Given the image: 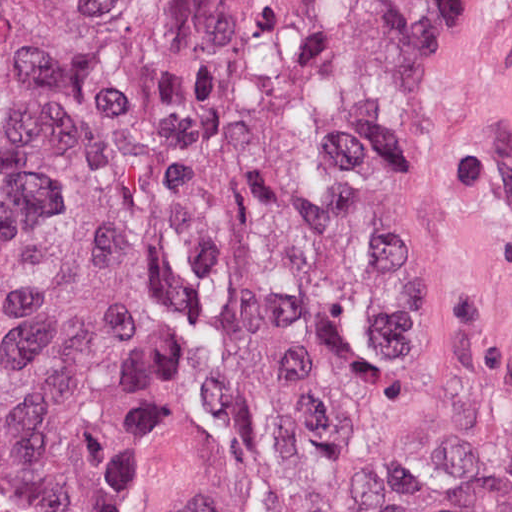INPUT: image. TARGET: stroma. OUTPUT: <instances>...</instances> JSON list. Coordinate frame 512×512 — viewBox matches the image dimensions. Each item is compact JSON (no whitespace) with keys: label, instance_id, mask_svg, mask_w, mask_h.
I'll list each match as a JSON object with an SVG mask.
<instances>
[{"label":"stroma","instance_id":"obj_1","mask_svg":"<svg viewBox=\"0 0 512 512\" xmlns=\"http://www.w3.org/2000/svg\"><path fill=\"white\" fill-rule=\"evenodd\" d=\"M416 259L467 372L512 402V0H460L440 46L423 120ZM151 269L154 364L117 512H152L149 471L173 375L171 312Z\"/></svg>","mask_w":512,"mask_h":512}]
</instances>
